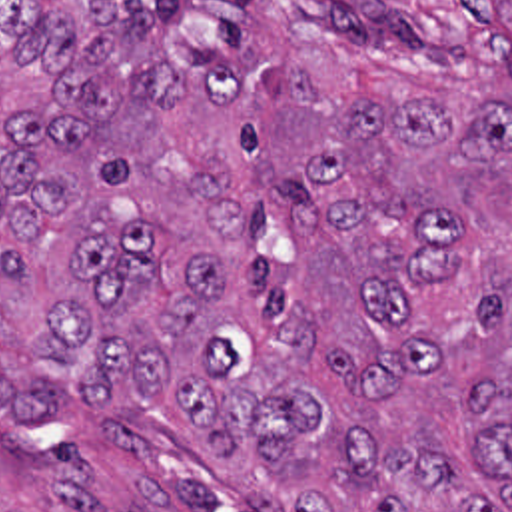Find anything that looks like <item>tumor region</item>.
I'll return each instance as SVG.
<instances>
[{"instance_id": "tumor-region-1", "label": "tumor region", "mask_w": 512, "mask_h": 512, "mask_svg": "<svg viewBox=\"0 0 512 512\" xmlns=\"http://www.w3.org/2000/svg\"><path fill=\"white\" fill-rule=\"evenodd\" d=\"M0 418L512 512V0H0Z\"/></svg>"}]
</instances>
